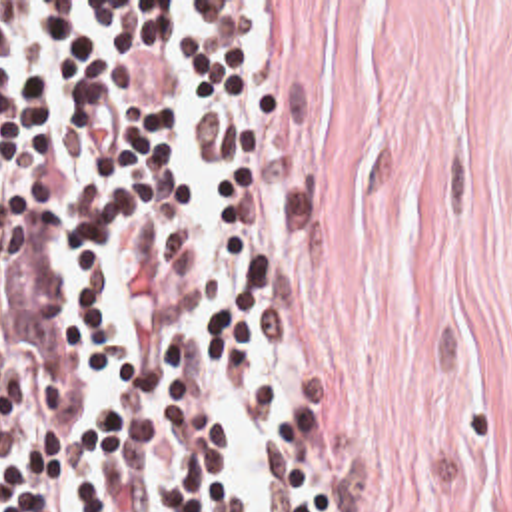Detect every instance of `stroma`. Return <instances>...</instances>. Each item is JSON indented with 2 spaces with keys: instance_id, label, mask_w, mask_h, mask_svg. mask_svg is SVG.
<instances>
[{
  "instance_id": "35a3bbf8",
  "label": "stroma",
  "mask_w": 512,
  "mask_h": 512,
  "mask_svg": "<svg viewBox=\"0 0 512 512\" xmlns=\"http://www.w3.org/2000/svg\"><path fill=\"white\" fill-rule=\"evenodd\" d=\"M264 20L270 321L346 512H512V0Z\"/></svg>"
}]
</instances>
